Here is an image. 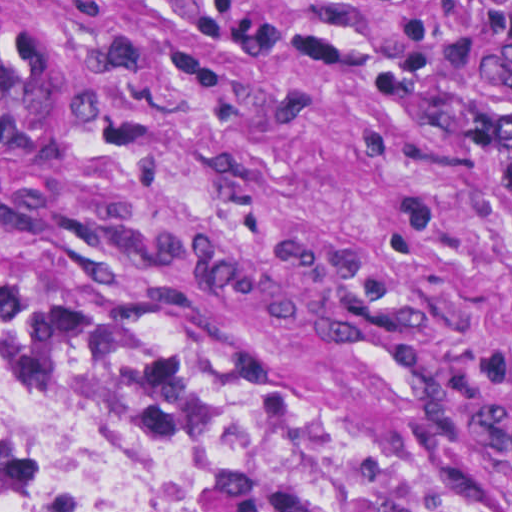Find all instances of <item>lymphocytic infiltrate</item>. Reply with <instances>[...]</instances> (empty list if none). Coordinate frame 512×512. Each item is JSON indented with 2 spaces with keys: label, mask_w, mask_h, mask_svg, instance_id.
I'll use <instances>...</instances> for the list:
<instances>
[{
  "label": "lymphocytic infiltrate",
  "mask_w": 512,
  "mask_h": 512,
  "mask_svg": "<svg viewBox=\"0 0 512 512\" xmlns=\"http://www.w3.org/2000/svg\"><path fill=\"white\" fill-rule=\"evenodd\" d=\"M174 18L193 30L222 32L246 41L287 49L307 60L344 72L397 107L422 85L425 24L406 18L396 30V55L390 67L372 72L356 45L246 18L230 0H210ZM475 8L473 32L457 44L455 56L473 88L468 109L446 107L439 123L454 140L487 155L501 169L500 186L512 192V0H464Z\"/></svg>",
  "instance_id": "f902f5d3"
}]
</instances>
